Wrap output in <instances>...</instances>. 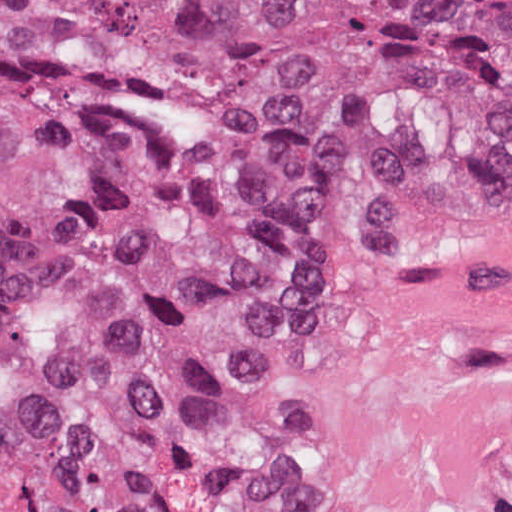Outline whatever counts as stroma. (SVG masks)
<instances>
[{
	"mask_svg": "<svg viewBox=\"0 0 512 512\" xmlns=\"http://www.w3.org/2000/svg\"><path fill=\"white\" fill-rule=\"evenodd\" d=\"M343 257L301 265L266 282L238 309L230 352V419L255 512H290L269 483V346L274 326L295 296Z\"/></svg>",
	"mask_w": 512,
	"mask_h": 512,
	"instance_id": "stroma-1",
	"label": "stroma"
}]
</instances>
